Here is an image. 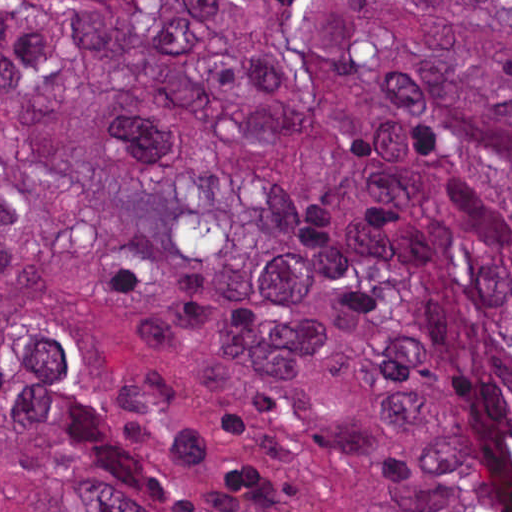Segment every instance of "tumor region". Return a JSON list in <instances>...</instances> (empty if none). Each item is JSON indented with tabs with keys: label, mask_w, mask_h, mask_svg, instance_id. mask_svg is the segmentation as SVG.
<instances>
[{
	"label": "tumor region",
	"mask_w": 512,
	"mask_h": 512,
	"mask_svg": "<svg viewBox=\"0 0 512 512\" xmlns=\"http://www.w3.org/2000/svg\"><path fill=\"white\" fill-rule=\"evenodd\" d=\"M0 512H512V0H0Z\"/></svg>",
	"instance_id": "e687c5a6"
}]
</instances>
